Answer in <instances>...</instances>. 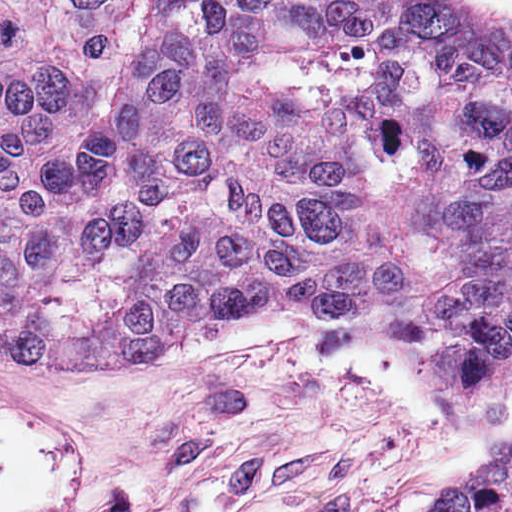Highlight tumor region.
Returning <instances> with one entry per match:
<instances>
[{
	"label": "tumor region",
	"mask_w": 512,
	"mask_h": 512,
	"mask_svg": "<svg viewBox=\"0 0 512 512\" xmlns=\"http://www.w3.org/2000/svg\"><path fill=\"white\" fill-rule=\"evenodd\" d=\"M332 312L426 353L452 407L512 396V11L194 0ZM433 512H512V455Z\"/></svg>",
	"instance_id": "obj_1"
}]
</instances>
